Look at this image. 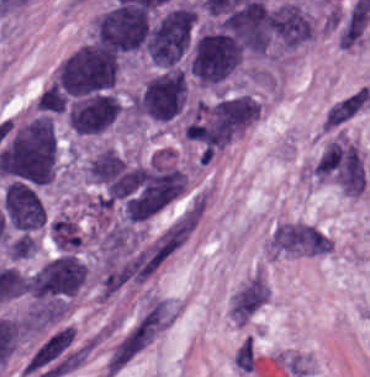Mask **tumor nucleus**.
Segmentation results:
<instances>
[{"label":"tumor nucleus","mask_w":370,"mask_h":377,"mask_svg":"<svg viewBox=\"0 0 370 377\" xmlns=\"http://www.w3.org/2000/svg\"><path fill=\"white\" fill-rule=\"evenodd\" d=\"M91 41L115 52L144 49V7L114 3L94 15L91 23Z\"/></svg>","instance_id":"2f306a5c"},{"label":"tumor nucleus","mask_w":370,"mask_h":377,"mask_svg":"<svg viewBox=\"0 0 370 377\" xmlns=\"http://www.w3.org/2000/svg\"><path fill=\"white\" fill-rule=\"evenodd\" d=\"M134 115L156 123H169L184 113L185 75L172 67L148 80L133 98Z\"/></svg>","instance_id":"8643909e"},{"label":"tumor nucleus","mask_w":370,"mask_h":377,"mask_svg":"<svg viewBox=\"0 0 370 377\" xmlns=\"http://www.w3.org/2000/svg\"><path fill=\"white\" fill-rule=\"evenodd\" d=\"M87 278V265L72 254L52 257L30 277L33 302H65L76 299Z\"/></svg>","instance_id":"5ab6c2c4"},{"label":"tumor nucleus","mask_w":370,"mask_h":377,"mask_svg":"<svg viewBox=\"0 0 370 377\" xmlns=\"http://www.w3.org/2000/svg\"><path fill=\"white\" fill-rule=\"evenodd\" d=\"M3 219L17 235H31L43 229L46 210L36 188L28 183L9 181L1 197Z\"/></svg>","instance_id":"2cbd58db"},{"label":"tumor nucleus","mask_w":370,"mask_h":377,"mask_svg":"<svg viewBox=\"0 0 370 377\" xmlns=\"http://www.w3.org/2000/svg\"><path fill=\"white\" fill-rule=\"evenodd\" d=\"M266 46L273 51H293L313 36V19L293 1L265 11Z\"/></svg>","instance_id":"3d1891a8"},{"label":"tumor nucleus","mask_w":370,"mask_h":377,"mask_svg":"<svg viewBox=\"0 0 370 377\" xmlns=\"http://www.w3.org/2000/svg\"><path fill=\"white\" fill-rule=\"evenodd\" d=\"M119 115L120 103L113 91L71 99L67 106L69 127L81 137L105 134Z\"/></svg>","instance_id":"2083b535"},{"label":"tumor nucleus","mask_w":370,"mask_h":377,"mask_svg":"<svg viewBox=\"0 0 370 377\" xmlns=\"http://www.w3.org/2000/svg\"><path fill=\"white\" fill-rule=\"evenodd\" d=\"M119 66L120 61L115 54L61 92L72 98L111 92L118 80Z\"/></svg>","instance_id":"8087334f"}]
</instances>
